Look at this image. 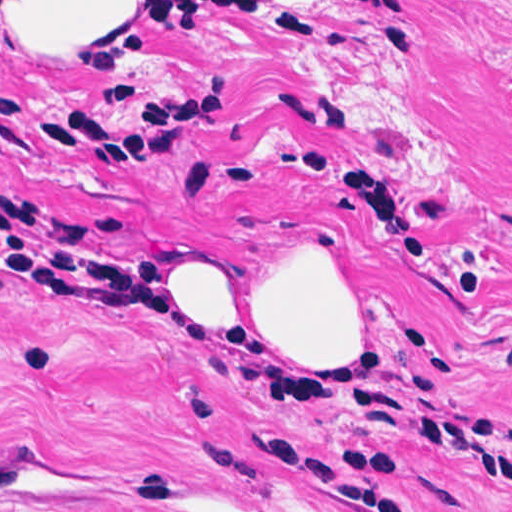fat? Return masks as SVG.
Instances as JSON below:
<instances>
[{
	"label": "fat",
	"instance_id": "1",
	"mask_svg": "<svg viewBox=\"0 0 512 512\" xmlns=\"http://www.w3.org/2000/svg\"><path fill=\"white\" fill-rule=\"evenodd\" d=\"M153 1L0 0V9L36 49L53 53L95 38ZM168 281L193 318H137V331L233 333L328 368L350 364L364 342L359 290L327 264H304L281 273L256 320H243L240 275L226 257L186 259L170 270Z\"/></svg>",
	"mask_w": 512,
	"mask_h": 512
}]
</instances>
